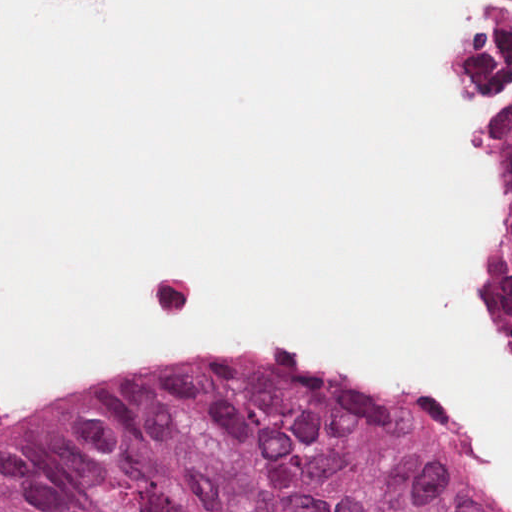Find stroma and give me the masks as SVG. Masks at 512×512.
<instances>
[{
    "label": "stroma",
    "instance_id": "35a3bbf8",
    "mask_svg": "<svg viewBox=\"0 0 512 512\" xmlns=\"http://www.w3.org/2000/svg\"><path fill=\"white\" fill-rule=\"evenodd\" d=\"M480 1H512V0H480ZM477 96H478V94H477ZM478 98H479L480 102L482 103V105L485 107V104L481 100V98L479 96H478ZM499 228H500V220H499L498 206H497L495 199L493 197V194L490 190V239H489V246H488V256L498 238ZM487 262H488V259H487ZM487 262H486V264H487ZM486 264H485V267H486ZM485 267H484V270H485ZM484 270H483V272H484ZM481 277H482V275H481ZM170 362H175V361H152V362H148V363L139 364V365H136V366L114 376L110 380L127 377V376L133 375L137 372L146 370L148 368L166 364V363H170Z\"/></svg>",
    "mask_w": 512,
    "mask_h": 512
}]
</instances>
